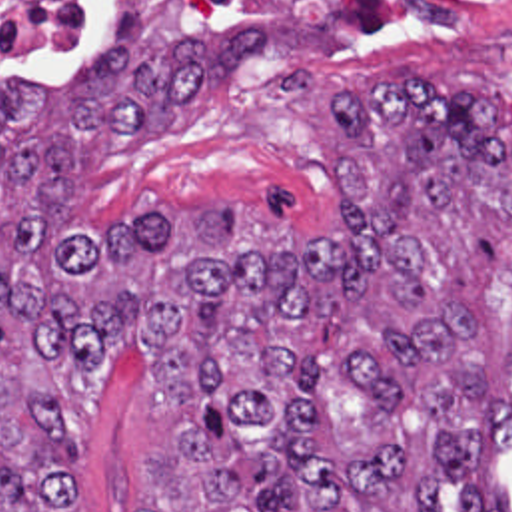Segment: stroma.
Instances as JSON below:
<instances>
[{"label":"stroma","instance_id":"obj_1","mask_svg":"<svg viewBox=\"0 0 512 512\" xmlns=\"http://www.w3.org/2000/svg\"><path fill=\"white\" fill-rule=\"evenodd\" d=\"M113 1H101L65 35L0 41V79L15 69L77 79L107 31ZM237 27L263 29L267 51L177 101L175 121L93 131L75 193L77 225L101 233L145 201L175 199L245 203L259 217L249 223L331 225L339 219L333 171L351 145L333 103L349 89L409 71L435 73L443 85L465 77L489 85L509 99L499 133L512 139V33H271L221 0H155L149 11L155 45L193 37L209 47ZM155 361L153 349L119 347L75 363L63 377L83 426V480L71 512H139L163 452V420L139 399ZM481 470L497 472L512 498V444L477 460L471 476ZM465 482L441 486L445 512H465Z\"/></svg>","mask_w":512,"mask_h":512}]
</instances>
